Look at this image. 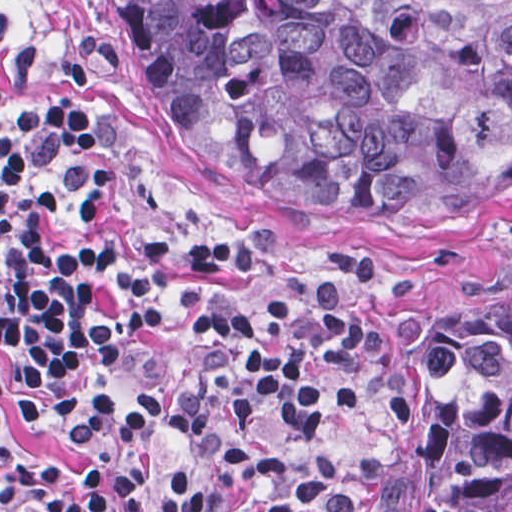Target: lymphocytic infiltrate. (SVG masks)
Returning <instances> with one entry per match:
<instances>
[{
	"label": "lymphocytic infiltrate",
	"mask_w": 512,
	"mask_h": 512,
	"mask_svg": "<svg viewBox=\"0 0 512 512\" xmlns=\"http://www.w3.org/2000/svg\"><path fill=\"white\" fill-rule=\"evenodd\" d=\"M1 59V93L35 68ZM62 71L94 77L84 31ZM282 227L150 215L82 109L43 97L1 127V369L23 422L62 432L87 476L1 440V512H125L157 431L187 435L156 512H354L333 452L373 332V290L247 295Z\"/></svg>",
	"instance_id": "obj_1"
}]
</instances>
